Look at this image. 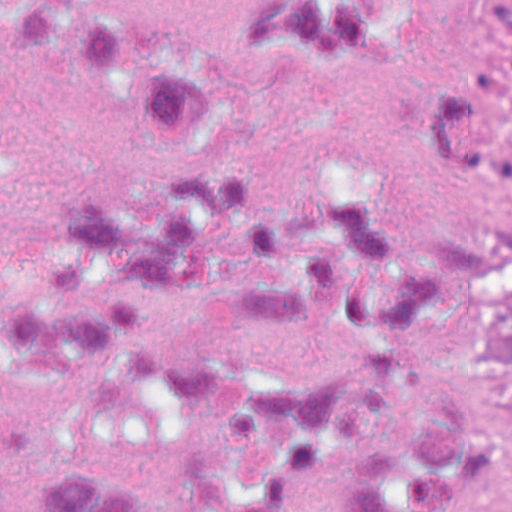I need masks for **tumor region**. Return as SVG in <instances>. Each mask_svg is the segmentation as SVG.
I'll return each instance as SVG.
<instances>
[{
  "label": "tumor region",
  "mask_w": 512,
  "mask_h": 512,
  "mask_svg": "<svg viewBox=\"0 0 512 512\" xmlns=\"http://www.w3.org/2000/svg\"><path fill=\"white\" fill-rule=\"evenodd\" d=\"M407 153L445 196L512 212V0L472 18L469 51L412 114ZM471 316V437L491 473L512 429V219L465 231Z\"/></svg>",
  "instance_id": "tumor-region-1"
}]
</instances>
